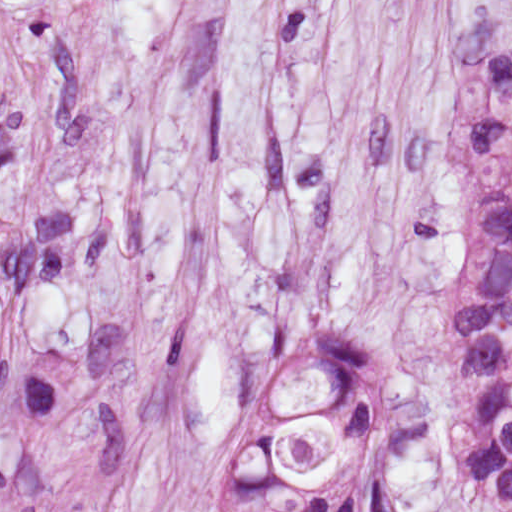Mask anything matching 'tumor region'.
I'll return each instance as SVG.
<instances>
[{
    "label": "tumor region",
    "instance_id": "e687c5a6",
    "mask_svg": "<svg viewBox=\"0 0 512 512\" xmlns=\"http://www.w3.org/2000/svg\"><path fill=\"white\" fill-rule=\"evenodd\" d=\"M480 252L455 336L449 441L475 489L512 512V84L474 113ZM404 415L394 368L356 343L285 354L213 512H363Z\"/></svg>",
    "mask_w": 512,
    "mask_h": 512
}]
</instances>
